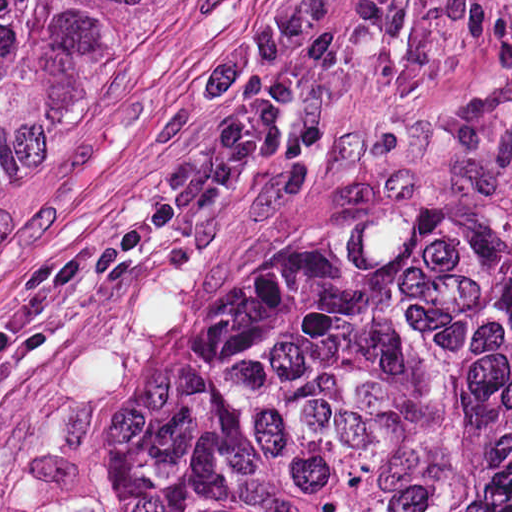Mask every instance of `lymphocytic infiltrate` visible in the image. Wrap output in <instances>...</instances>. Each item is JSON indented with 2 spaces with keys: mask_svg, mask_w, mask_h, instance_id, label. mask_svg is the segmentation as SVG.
Masks as SVG:
<instances>
[{
  "mask_svg": "<svg viewBox=\"0 0 512 512\" xmlns=\"http://www.w3.org/2000/svg\"><path fill=\"white\" fill-rule=\"evenodd\" d=\"M437 1L318 0L288 25L224 48L189 78L211 114L193 158L163 196L118 221L106 242L120 258L175 253L255 178L284 106L351 79L381 40L426 19Z\"/></svg>",
  "mask_w": 512,
  "mask_h": 512,
  "instance_id": "f902f5d3",
  "label": "lymphocytic infiltrate"
}]
</instances>
